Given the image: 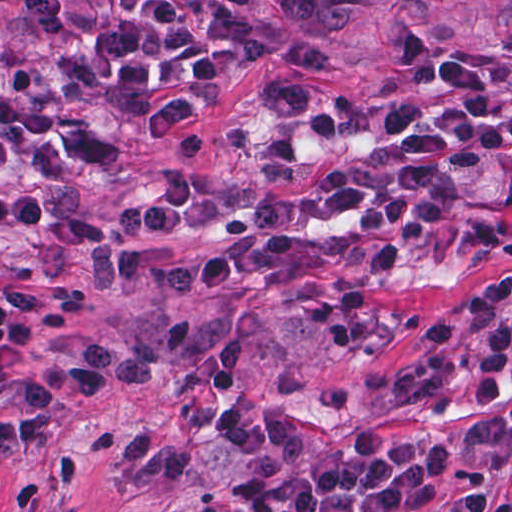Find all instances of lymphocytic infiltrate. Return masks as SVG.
Returning a JSON list of instances; mask_svg holds the SVG:
<instances>
[{
	"label": "lymphocytic infiltrate",
	"mask_w": 512,
	"mask_h": 512,
	"mask_svg": "<svg viewBox=\"0 0 512 512\" xmlns=\"http://www.w3.org/2000/svg\"><path fill=\"white\" fill-rule=\"evenodd\" d=\"M33 36L25 63L0 60V197L91 175L106 154L98 120L155 121L209 100L252 65L247 36L207 0H17ZM320 83L277 79L220 143L215 191L173 170L111 213L56 211L25 194L0 199L7 240H31L132 290L186 301L229 289L298 300L323 330L366 357L389 350V294L405 286L396 251L356 248L289 231L222 237L240 217L284 226L350 223L419 246L454 232L485 159L512 152V47L456 49L361 118L355 134L384 149L350 157L261 200L331 117ZM512 268L446 305L422 327L426 351L465 350L477 394L498 413L509 400ZM512 422V410L510 414ZM246 512H418L435 504L449 444L353 433L348 452L318 456L308 436L271 420L233 427ZM454 512H511L483 487H464Z\"/></svg>",
	"instance_id": "lymphocytic-infiltrate-1"
}]
</instances>
